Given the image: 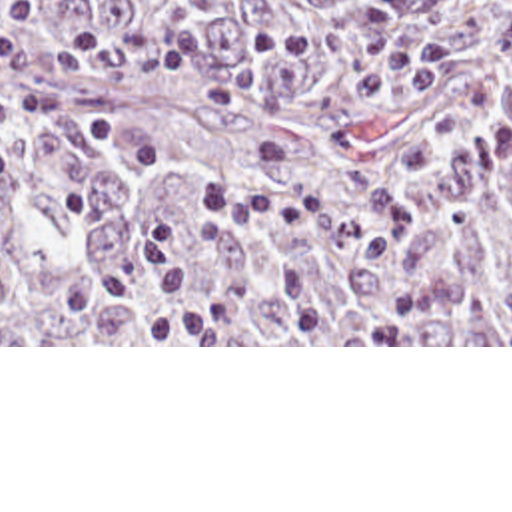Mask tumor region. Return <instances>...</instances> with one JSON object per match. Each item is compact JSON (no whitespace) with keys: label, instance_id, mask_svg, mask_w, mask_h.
Masks as SVG:
<instances>
[{"label":"tumor region","instance_id":"e687c5a6","mask_svg":"<svg viewBox=\"0 0 512 512\" xmlns=\"http://www.w3.org/2000/svg\"><path fill=\"white\" fill-rule=\"evenodd\" d=\"M197 24L235 111L157 71L24 67L0 345H512V0H0Z\"/></svg>","mask_w":512,"mask_h":512}]
</instances>
